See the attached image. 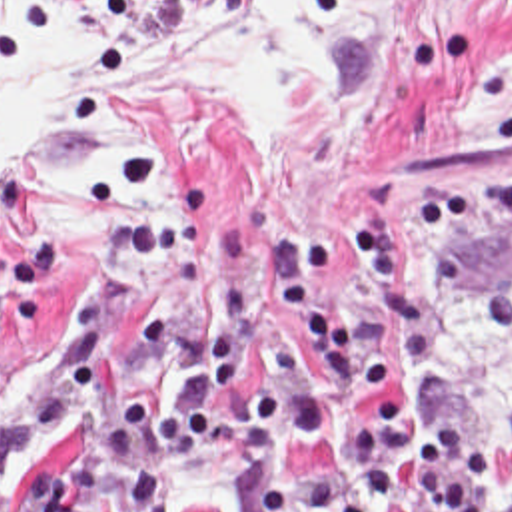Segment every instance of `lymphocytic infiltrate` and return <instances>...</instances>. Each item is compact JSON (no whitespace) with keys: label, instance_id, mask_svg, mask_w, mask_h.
Wrapping results in <instances>:
<instances>
[{"label":"lymphocytic infiltrate","instance_id":"1","mask_svg":"<svg viewBox=\"0 0 512 512\" xmlns=\"http://www.w3.org/2000/svg\"><path fill=\"white\" fill-rule=\"evenodd\" d=\"M414 217L424 265L410 261L408 227L376 211L372 289L346 319L314 285L360 255V219H280L260 253L246 227L226 221L208 231L212 253L176 251L164 283L202 301L196 351L160 412L146 418L142 394L120 396L62 480L32 470L0 496V512H160L182 462L212 450L236 396L264 454L334 444L312 490L260 484L256 512H512V428L500 438L446 420L394 382L424 347L436 299L458 295L512 331V247L494 279L472 269L478 235L512 227V165L466 197L434 199L426 185Z\"/></svg>","mask_w":512,"mask_h":512}]
</instances>
